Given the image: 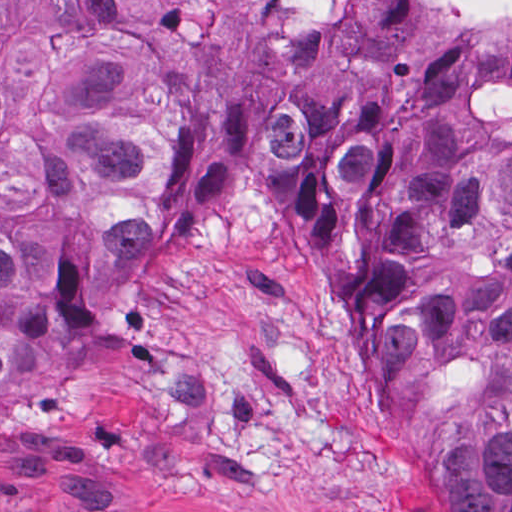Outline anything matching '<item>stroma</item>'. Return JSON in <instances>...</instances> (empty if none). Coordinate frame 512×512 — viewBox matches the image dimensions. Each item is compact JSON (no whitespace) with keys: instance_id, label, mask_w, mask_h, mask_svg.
Returning <instances> with one entry per match:
<instances>
[{"instance_id":"stroma-1","label":"stroma","mask_w":512,"mask_h":512,"mask_svg":"<svg viewBox=\"0 0 512 512\" xmlns=\"http://www.w3.org/2000/svg\"><path fill=\"white\" fill-rule=\"evenodd\" d=\"M387 425L436 475L228 194L185 233L162 212L36 322L0 387V512H466Z\"/></svg>"}]
</instances>
